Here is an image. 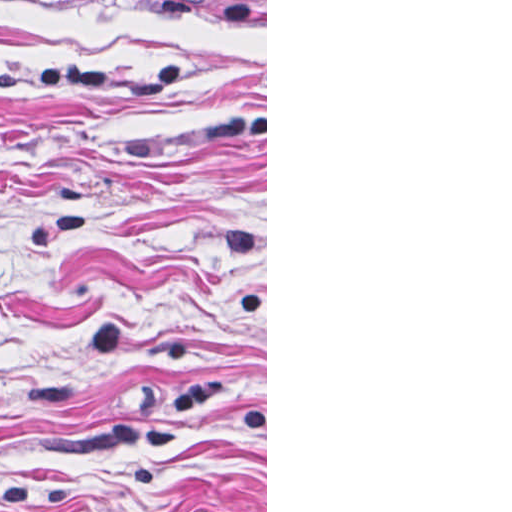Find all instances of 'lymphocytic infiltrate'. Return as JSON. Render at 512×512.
I'll return each mask as SVG.
<instances>
[{
    "label": "lymphocytic infiltrate",
    "mask_w": 512,
    "mask_h": 512,
    "mask_svg": "<svg viewBox=\"0 0 512 512\" xmlns=\"http://www.w3.org/2000/svg\"><path fill=\"white\" fill-rule=\"evenodd\" d=\"M38 1V0H0ZM221 16L233 26L249 24V0H218Z\"/></svg>",
    "instance_id": "obj_1"
}]
</instances>
